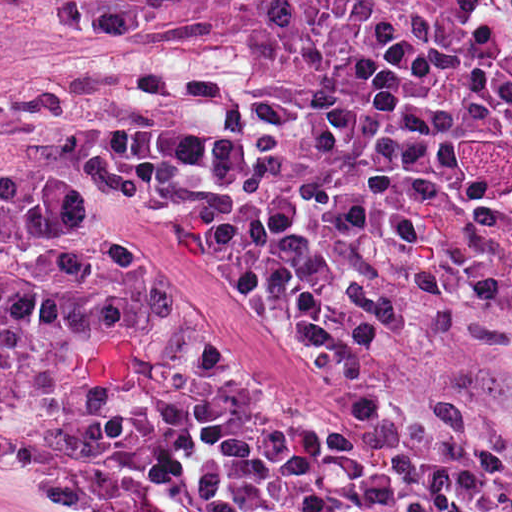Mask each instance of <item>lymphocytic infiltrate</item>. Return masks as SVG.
<instances>
[{"label": "lymphocytic infiltrate", "instance_id": "obj_1", "mask_svg": "<svg viewBox=\"0 0 512 512\" xmlns=\"http://www.w3.org/2000/svg\"><path fill=\"white\" fill-rule=\"evenodd\" d=\"M46 136L293 293L345 429L191 362L102 240L0 214V433L71 489L512 512V0H264L243 70L55 77Z\"/></svg>", "mask_w": 512, "mask_h": 512}]
</instances>
